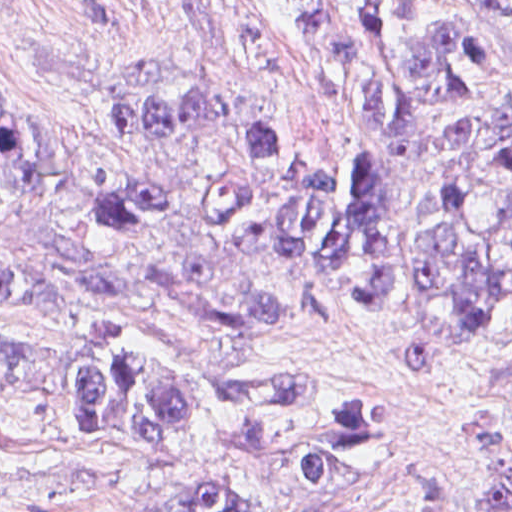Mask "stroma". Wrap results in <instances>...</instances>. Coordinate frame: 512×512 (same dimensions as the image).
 Returning a JSON list of instances; mask_svg holds the SVG:
<instances>
[{
	"label": "stroma",
	"mask_w": 512,
	"mask_h": 512,
	"mask_svg": "<svg viewBox=\"0 0 512 512\" xmlns=\"http://www.w3.org/2000/svg\"><path fill=\"white\" fill-rule=\"evenodd\" d=\"M249 1L291 48L290 72L242 46L225 0H0V81L68 109L125 85H209L316 150L376 145L351 125L259 1ZM463 1L480 8L512 67V0ZM474 29L496 70V51ZM501 87L492 106L471 115L512 132V83ZM269 278L282 317L264 354L284 370L290 392H367L377 400L384 454L372 472L340 485H305L284 467L280 447L315 419L300 418L262 451L239 453L212 443L200 403L181 456L143 463L84 437L66 394L0 389V512H132L204 482L248 492L256 512H347L416 490L432 495L435 512L505 510L512 500V329L471 333L434 313L372 302L315 271ZM103 325L159 353L191 347L163 309L145 306H81L50 322H15L0 311V340L70 351L82 332Z\"/></svg>",
	"instance_id": "stroma-1"
}]
</instances>
